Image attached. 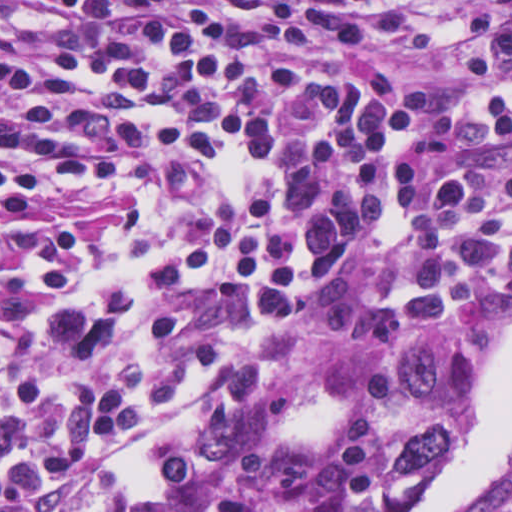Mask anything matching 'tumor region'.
Here are the masks:
<instances>
[{
    "instance_id": "obj_1",
    "label": "tumor region",
    "mask_w": 512,
    "mask_h": 512,
    "mask_svg": "<svg viewBox=\"0 0 512 512\" xmlns=\"http://www.w3.org/2000/svg\"><path fill=\"white\" fill-rule=\"evenodd\" d=\"M400 421L382 466L388 494L414 490L450 440L460 412V354L444 335L412 334L388 355Z\"/></svg>"
}]
</instances>
